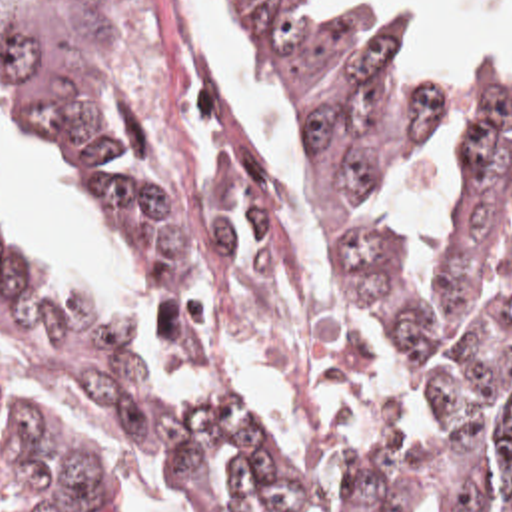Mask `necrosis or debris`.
Masks as SVG:
<instances>
[{"mask_svg":"<svg viewBox=\"0 0 512 512\" xmlns=\"http://www.w3.org/2000/svg\"><path fill=\"white\" fill-rule=\"evenodd\" d=\"M117 5L131 31L137 67L161 97L169 137L189 153L241 143L247 127L197 57L181 0H117Z\"/></svg>","mask_w":512,"mask_h":512,"instance_id":"obj_1","label":"necrosis or debris"}]
</instances>
